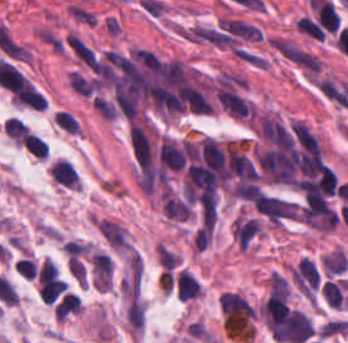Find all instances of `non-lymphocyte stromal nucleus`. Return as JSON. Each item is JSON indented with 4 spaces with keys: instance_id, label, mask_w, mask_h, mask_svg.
I'll use <instances>...</instances> for the list:
<instances>
[{
    "instance_id": "1",
    "label": "non-lymphocyte stromal nucleus",
    "mask_w": 348,
    "mask_h": 343,
    "mask_svg": "<svg viewBox=\"0 0 348 343\" xmlns=\"http://www.w3.org/2000/svg\"><path fill=\"white\" fill-rule=\"evenodd\" d=\"M94 225L104 242L111 249L119 251H127L131 249L127 232L120 224L104 218L94 223Z\"/></svg>"
},
{
    "instance_id": "2",
    "label": "non-lymphocyte stromal nucleus",
    "mask_w": 348,
    "mask_h": 343,
    "mask_svg": "<svg viewBox=\"0 0 348 343\" xmlns=\"http://www.w3.org/2000/svg\"><path fill=\"white\" fill-rule=\"evenodd\" d=\"M321 264L326 275L345 270L348 265V257L338 245L321 254Z\"/></svg>"
},
{
    "instance_id": "3",
    "label": "non-lymphocyte stromal nucleus",
    "mask_w": 348,
    "mask_h": 343,
    "mask_svg": "<svg viewBox=\"0 0 348 343\" xmlns=\"http://www.w3.org/2000/svg\"><path fill=\"white\" fill-rule=\"evenodd\" d=\"M267 289L269 294L281 296V297H287L289 294V287L285 281V279L282 277V275L276 270L272 269L268 277L265 279Z\"/></svg>"
},
{
    "instance_id": "4",
    "label": "non-lymphocyte stromal nucleus",
    "mask_w": 348,
    "mask_h": 343,
    "mask_svg": "<svg viewBox=\"0 0 348 343\" xmlns=\"http://www.w3.org/2000/svg\"><path fill=\"white\" fill-rule=\"evenodd\" d=\"M156 259L160 266L170 269L173 264L179 259V254L173 251L165 244L156 240L155 242Z\"/></svg>"
}]
</instances>
